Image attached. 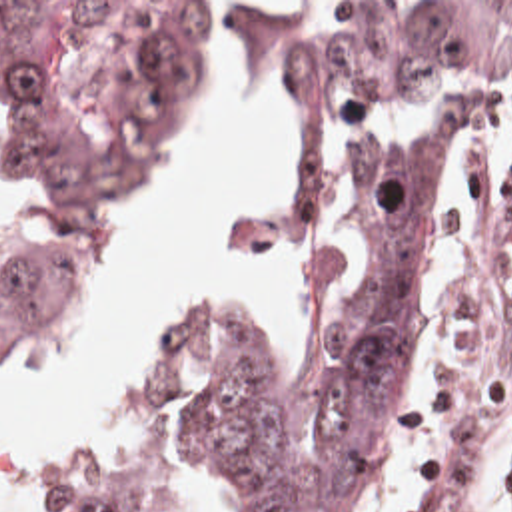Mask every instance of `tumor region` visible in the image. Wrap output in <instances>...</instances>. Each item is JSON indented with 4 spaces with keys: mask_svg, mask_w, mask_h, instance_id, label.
Masks as SVG:
<instances>
[{
    "mask_svg": "<svg viewBox=\"0 0 512 512\" xmlns=\"http://www.w3.org/2000/svg\"><path fill=\"white\" fill-rule=\"evenodd\" d=\"M162 2H0V319L58 311L136 184L182 60ZM512 48V0H386L290 38L278 84L334 200L310 254V337L292 377L222 341L182 345L96 512H132L174 455L238 512H348L392 439L450 190L481 112L473 78ZM432 104L396 140L374 114ZM481 435L452 439L420 512H469ZM512 485V453L497 487Z\"/></svg>",
    "mask_w": 512,
    "mask_h": 512,
    "instance_id": "obj_1",
    "label": "tumor region"
}]
</instances>
